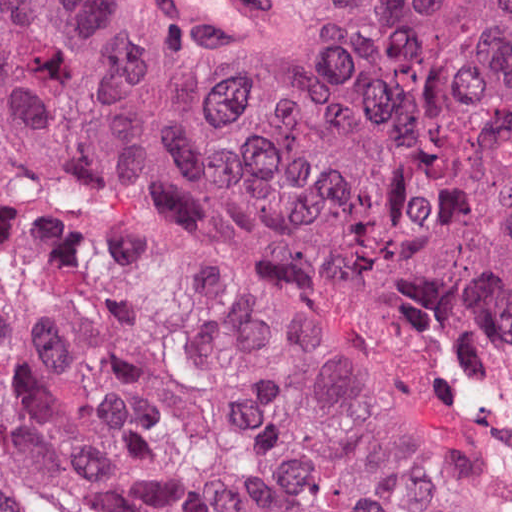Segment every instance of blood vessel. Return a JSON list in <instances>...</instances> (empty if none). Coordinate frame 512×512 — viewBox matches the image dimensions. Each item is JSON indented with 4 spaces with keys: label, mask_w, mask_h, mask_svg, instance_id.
Segmentation results:
<instances>
[{
    "label": "blood vessel",
    "mask_w": 512,
    "mask_h": 512,
    "mask_svg": "<svg viewBox=\"0 0 512 512\" xmlns=\"http://www.w3.org/2000/svg\"><path fill=\"white\" fill-rule=\"evenodd\" d=\"M171 29L193 39H247L277 22L266 0H144Z\"/></svg>",
    "instance_id": "obj_1"
}]
</instances>
